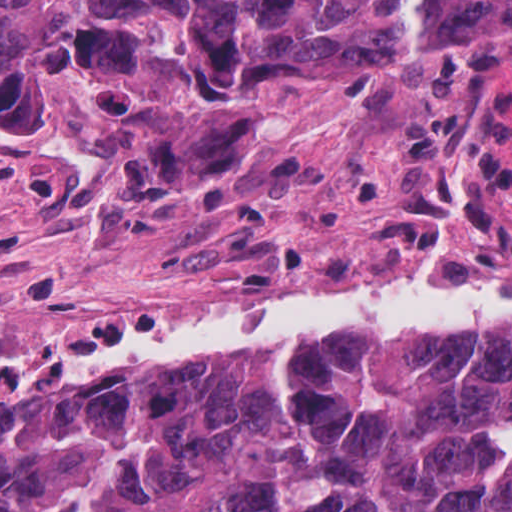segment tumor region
Masks as SVG:
<instances>
[{"instance_id": "obj_1", "label": "tumor region", "mask_w": 512, "mask_h": 512, "mask_svg": "<svg viewBox=\"0 0 512 512\" xmlns=\"http://www.w3.org/2000/svg\"><path fill=\"white\" fill-rule=\"evenodd\" d=\"M0 0V111L139 112L184 158L253 91L369 80L447 47L512 57V0ZM63 372V371H62ZM0 384V512H512V322L345 329Z\"/></svg>"}]
</instances>
